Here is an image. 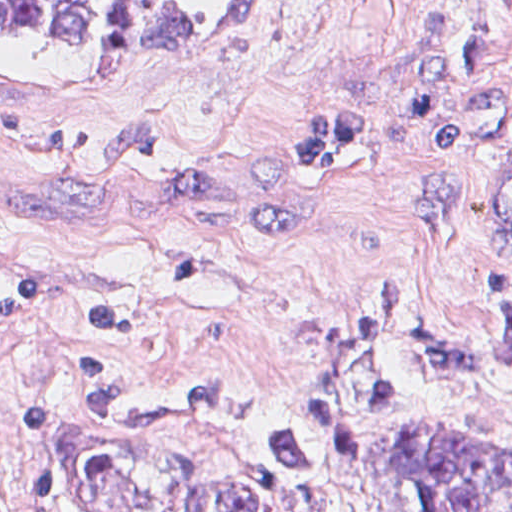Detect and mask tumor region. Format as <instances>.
I'll return each mask as SVG.
<instances>
[{
	"instance_id": "1",
	"label": "tumor region",
	"mask_w": 512,
	"mask_h": 512,
	"mask_svg": "<svg viewBox=\"0 0 512 512\" xmlns=\"http://www.w3.org/2000/svg\"><path fill=\"white\" fill-rule=\"evenodd\" d=\"M269 0H0V33L96 46L192 41ZM479 32L425 52L384 86L317 101L286 152L299 189L335 195L370 167L386 114L418 105L437 164L412 206L428 249L512 252V0H484ZM489 380L512 386V293L496 335L466 342L399 270L330 344L286 373L229 438L221 479H175L146 512H322L290 494L351 469L364 426L411 397ZM391 512H512V443L457 417H402L372 441Z\"/></svg>"
}]
</instances>
